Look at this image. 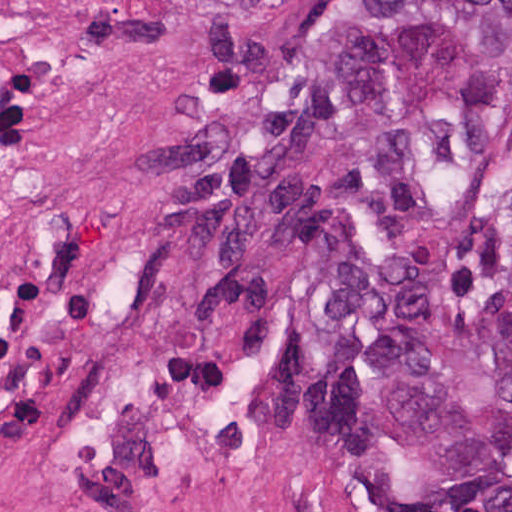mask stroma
Returning a JSON list of instances; mask_svg holds the SVG:
<instances>
[{
	"mask_svg": "<svg viewBox=\"0 0 512 512\" xmlns=\"http://www.w3.org/2000/svg\"><path fill=\"white\" fill-rule=\"evenodd\" d=\"M25 1L148 60L181 139L71 290L0 343V512H463L405 451L337 445L316 429L303 314L277 245L249 241L235 265L263 286L277 340L228 358L192 317L164 222L158 193L198 92L322 34L339 0Z\"/></svg>",
	"mask_w": 512,
	"mask_h": 512,
	"instance_id": "1",
	"label": "stroma"
}]
</instances>
